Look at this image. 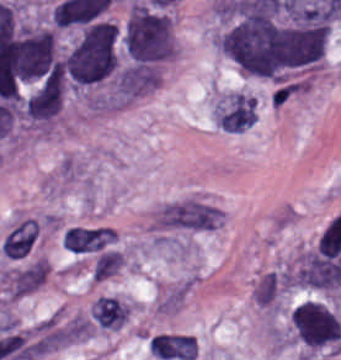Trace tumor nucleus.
<instances>
[{
  "label": "tumor nucleus",
  "mask_w": 341,
  "mask_h": 360,
  "mask_svg": "<svg viewBox=\"0 0 341 360\" xmlns=\"http://www.w3.org/2000/svg\"><path fill=\"white\" fill-rule=\"evenodd\" d=\"M116 64V26L94 20L84 26L64 51L62 71L69 84H95L111 75Z\"/></svg>",
  "instance_id": "2f306a5c"
},
{
  "label": "tumor nucleus",
  "mask_w": 341,
  "mask_h": 360,
  "mask_svg": "<svg viewBox=\"0 0 341 360\" xmlns=\"http://www.w3.org/2000/svg\"><path fill=\"white\" fill-rule=\"evenodd\" d=\"M125 56L132 63L159 64L168 59L174 47L170 15L140 1H134L120 30Z\"/></svg>",
  "instance_id": "8643909e"
},
{
  "label": "tumor nucleus",
  "mask_w": 341,
  "mask_h": 360,
  "mask_svg": "<svg viewBox=\"0 0 341 360\" xmlns=\"http://www.w3.org/2000/svg\"><path fill=\"white\" fill-rule=\"evenodd\" d=\"M290 322L296 340L312 351L336 353L341 348V323L326 304L305 299L293 308Z\"/></svg>",
  "instance_id": "5ab6c2c4"
},
{
  "label": "tumor nucleus",
  "mask_w": 341,
  "mask_h": 360,
  "mask_svg": "<svg viewBox=\"0 0 341 360\" xmlns=\"http://www.w3.org/2000/svg\"><path fill=\"white\" fill-rule=\"evenodd\" d=\"M123 255L115 250H108L98 256L93 271L94 280L102 281L103 279L114 274L122 265Z\"/></svg>",
  "instance_id": "2cbd58db"
}]
</instances>
